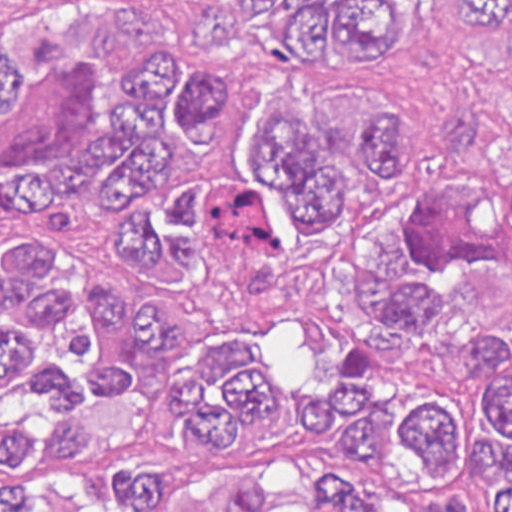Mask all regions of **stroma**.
<instances>
[{
    "mask_svg": "<svg viewBox=\"0 0 512 512\" xmlns=\"http://www.w3.org/2000/svg\"><path fill=\"white\" fill-rule=\"evenodd\" d=\"M247 57L252 117L226 136L231 163L254 118L317 92L323 67L308 73L275 62L267 16L234 0H206ZM56 5L69 12H124L144 0H0L1 27ZM346 77L368 98L400 102L413 114V175L391 200L345 202L340 229L377 205H464L489 198L499 165L512 160V68L481 53L460 23L455 0H425L394 19L393 43L375 69ZM1 206V196H0ZM431 263L463 306L488 327H512V249L479 217H443L422 237ZM298 249V314L252 335L268 365L284 371L298 400L293 423L257 460H223L176 449H147L156 464L186 477H256L310 445L327 383L349 361L342 323L327 300V248Z\"/></svg>",
    "mask_w": 512,
    "mask_h": 512,
    "instance_id": "35a3bbf8",
    "label": "stroma"
}]
</instances>
